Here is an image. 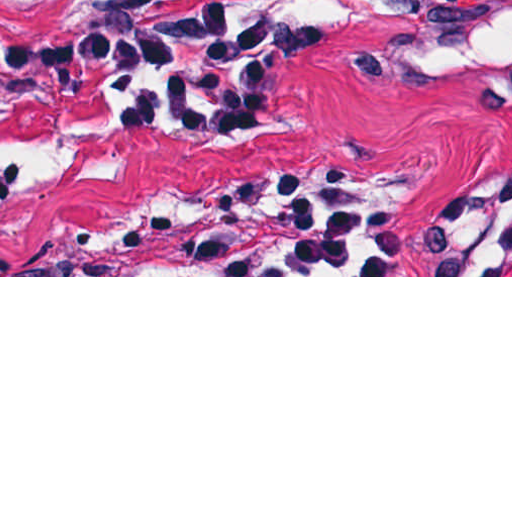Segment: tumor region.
Returning a JSON list of instances; mask_svg holds the SVG:
<instances>
[{
    "mask_svg": "<svg viewBox=\"0 0 512 512\" xmlns=\"http://www.w3.org/2000/svg\"><path fill=\"white\" fill-rule=\"evenodd\" d=\"M167 14H106L82 8H42L28 16L21 38L43 34H69L98 30L106 27H128L159 20ZM258 34V33H257ZM296 42L295 25L284 17L262 14V42L260 40V65L262 87L256 105L238 121L248 119L270 106L267 86V60L276 48ZM87 96L75 93L58 100H46L20 86V105L14 125L44 130L60 115ZM141 123L159 120L183 132L188 130L173 119L139 105H133Z\"/></svg>",
    "mask_w": 512,
    "mask_h": 512,
    "instance_id": "e687c5a6",
    "label": "tumor region"
}]
</instances>
